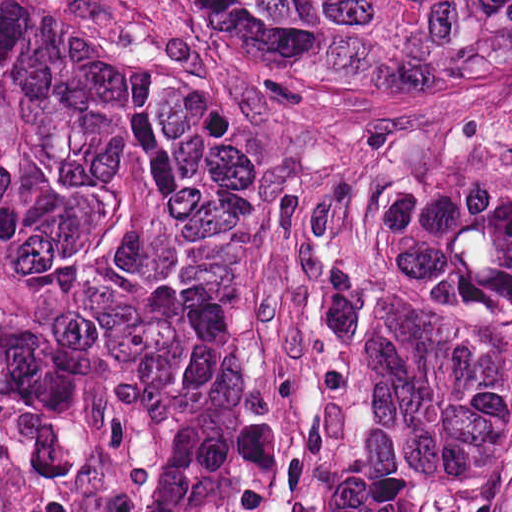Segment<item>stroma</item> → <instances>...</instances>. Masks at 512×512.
I'll return each mask as SVG.
<instances>
[{
	"instance_id": "35a3bbf8",
	"label": "stroma",
	"mask_w": 512,
	"mask_h": 512,
	"mask_svg": "<svg viewBox=\"0 0 512 512\" xmlns=\"http://www.w3.org/2000/svg\"><path fill=\"white\" fill-rule=\"evenodd\" d=\"M118 61L82 284L0 253V512H285L372 319L415 158L512 135V89L333 69L189 0H52Z\"/></svg>"
}]
</instances>
